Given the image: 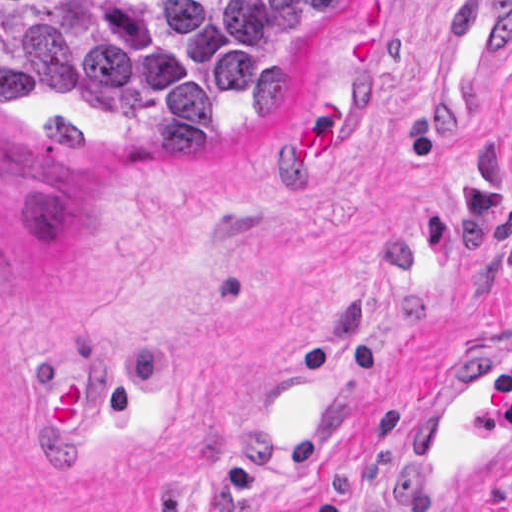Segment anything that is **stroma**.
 I'll return each instance as SVG.
<instances>
[{"mask_svg": "<svg viewBox=\"0 0 512 512\" xmlns=\"http://www.w3.org/2000/svg\"><path fill=\"white\" fill-rule=\"evenodd\" d=\"M478 1L340 0L313 82L228 146L152 143L90 88L0 110V512H404L422 381L512 347V21L469 129L422 123ZM66 355L90 358L92 422L54 459L41 401ZM312 358L318 438L244 461V400ZM479 510L512 512V482Z\"/></svg>", "mask_w": 512, "mask_h": 512, "instance_id": "35a3bbf8", "label": "stroma"}]
</instances>
